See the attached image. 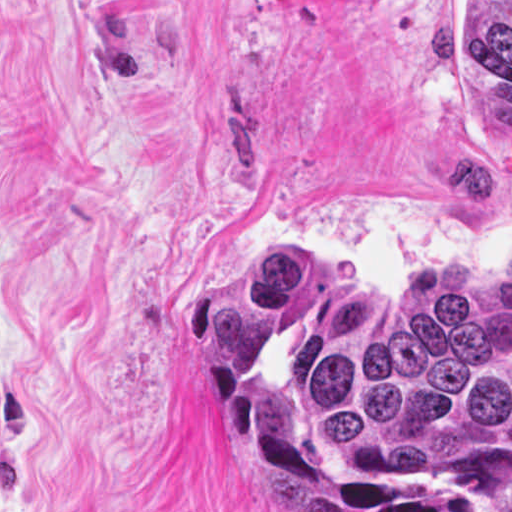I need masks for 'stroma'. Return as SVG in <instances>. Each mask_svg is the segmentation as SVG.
Returning a JSON list of instances; mask_svg holds the SVG:
<instances>
[{"label": "stroma", "mask_w": 512, "mask_h": 512, "mask_svg": "<svg viewBox=\"0 0 512 512\" xmlns=\"http://www.w3.org/2000/svg\"><path fill=\"white\" fill-rule=\"evenodd\" d=\"M265 249L334 321L512 254L466 0H0V512H267L179 342Z\"/></svg>", "instance_id": "obj_1"}]
</instances>
